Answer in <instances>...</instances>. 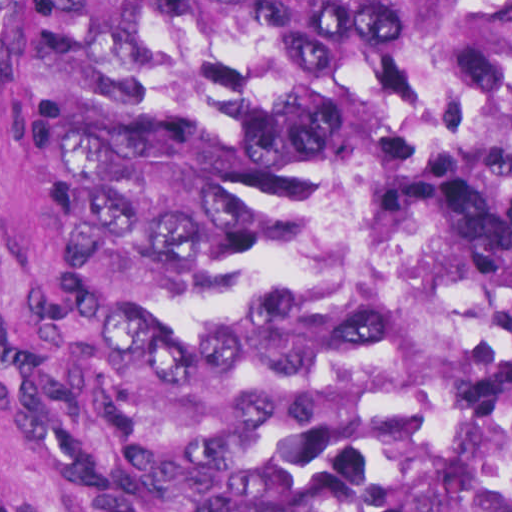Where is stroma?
Here are the masks:
<instances>
[{
  "label": "stroma",
  "mask_w": 512,
  "mask_h": 512,
  "mask_svg": "<svg viewBox=\"0 0 512 512\" xmlns=\"http://www.w3.org/2000/svg\"><path fill=\"white\" fill-rule=\"evenodd\" d=\"M1 1H512V0H0V512H68L36 461L26 421L1 195Z\"/></svg>",
  "instance_id": "obj_1"
}]
</instances>
